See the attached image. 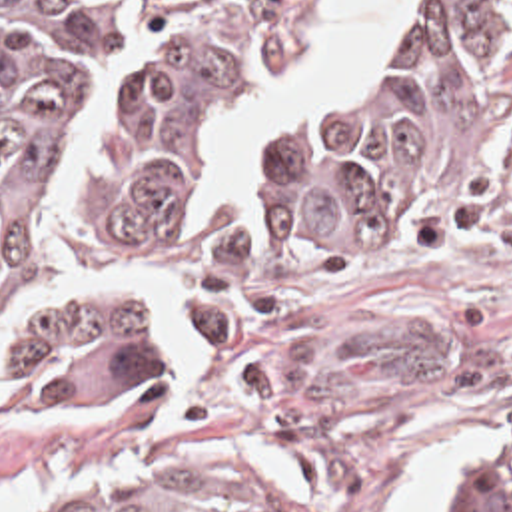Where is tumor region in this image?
<instances>
[{"mask_svg":"<svg viewBox=\"0 0 512 512\" xmlns=\"http://www.w3.org/2000/svg\"><path fill=\"white\" fill-rule=\"evenodd\" d=\"M323 0H0V391L16 407L166 399L154 325L209 349L283 297L461 213L512 141V0H431L371 75L273 133L259 209L190 247L217 155ZM24 512H277L211 466L76 476ZM429 512H505L491 476Z\"/></svg>","mask_w":512,"mask_h":512,"instance_id":"obj_1","label":"tumor region"}]
</instances>
